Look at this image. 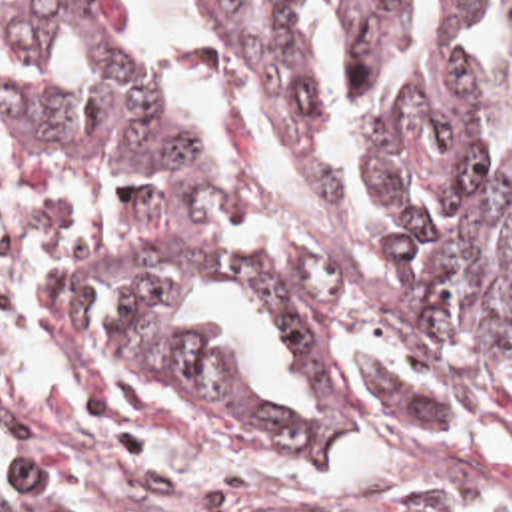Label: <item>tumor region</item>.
<instances>
[{"instance_id":"e687c5a6","label":"tumor region","mask_w":512,"mask_h":512,"mask_svg":"<svg viewBox=\"0 0 512 512\" xmlns=\"http://www.w3.org/2000/svg\"><path fill=\"white\" fill-rule=\"evenodd\" d=\"M483 0H439L469 24ZM512 2V0H511ZM263 114L285 174L299 160L311 188L345 200L351 186L327 146L307 0H201ZM415 0H339L349 90L389 64ZM79 76H27L14 100L16 188L137 192L159 208L145 248L87 262L61 290L65 332L145 370L219 394L231 410L273 420L295 452H341L399 434H512V152L487 162V70L451 50L389 104L375 138L387 202L385 248L371 266H333L305 250H235L203 192H273V184L203 148L179 102L133 52L113 0H16L0 24L10 52L43 54L63 36ZM255 296L283 338L317 348L339 328L387 334L441 376L479 416L461 428L433 402L371 368L383 406L359 408L319 368L295 376L315 420H299L245 378L211 336L185 334L177 304L205 278ZM111 280L109 332L75 334L87 288ZM243 512L173 497L87 452L53 444L0 414V512Z\"/></svg>"}]
</instances>
